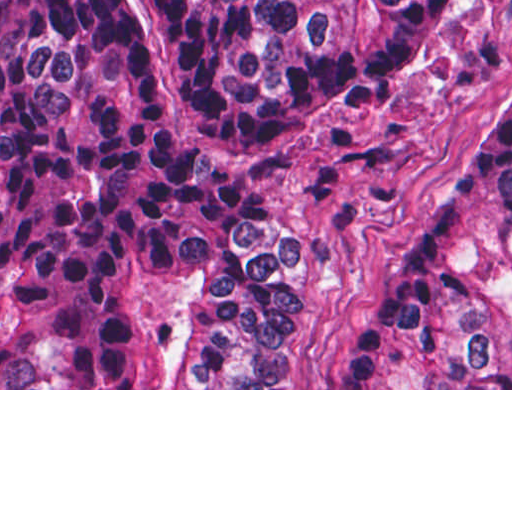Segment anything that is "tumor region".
I'll use <instances>...</instances> for the list:
<instances>
[{"instance_id":"e687c5a6","label":"tumor region","mask_w":512,"mask_h":512,"mask_svg":"<svg viewBox=\"0 0 512 512\" xmlns=\"http://www.w3.org/2000/svg\"><path fill=\"white\" fill-rule=\"evenodd\" d=\"M1 0V388H274L298 226L218 186L426 70L474 0ZM346 388H512V78Z\"/></svg>"}]
</instances>
